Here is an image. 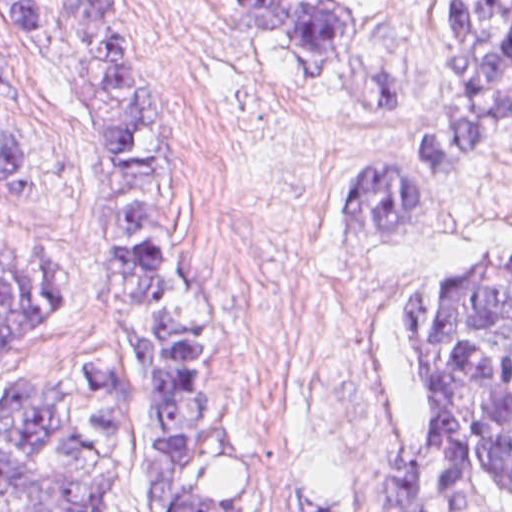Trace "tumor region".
<instances>
[{"mask_svg": "<svg viewBox=\"0 0 512 512\" xmlns=\"http://www.w3.org/2000/svg\"><path fill=\"white\" fill-rule=\"evenodd\" d=\"M71 73L105 147L115 314L128 353L18 374L0 396V512H117L132 454L140 512H311L233 494L231 405L209 376L211 326L187 214L200 155L173 120L120 0H54ZM239 33L303 73L354 70L355 17L328 0H225ZM31 40V0H0ZM455 94L340 185L343 239L409 236L423 198L512 117V0H455ZM0 169L24 184L0 119ZM60 304L50 251L0 248V349ZM416 434L389 452L362 512H512V241L408 290ZM134 398V399H133ZM133 399V400H132Z\"/></svg>", "mask_w": 512, "mask_h": 512, "instance_id": "obj_1", "label": "tumor region"}]
</instances>
